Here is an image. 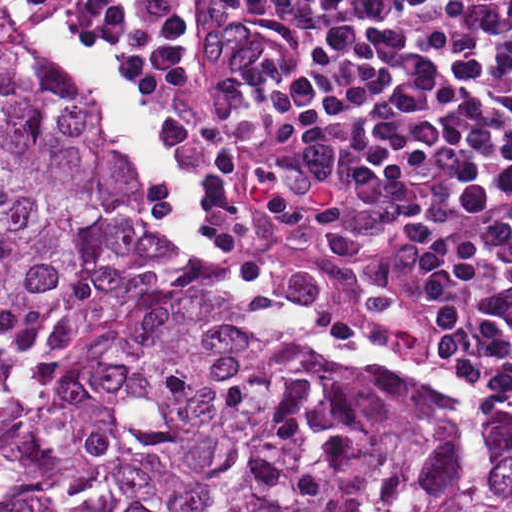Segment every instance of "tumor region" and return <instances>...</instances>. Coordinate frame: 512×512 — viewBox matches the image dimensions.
<instances>
[{
    "mask_svg": "<svg viewBox=\"0 0 512 512\" xmlns=\"http://www.w3.org/2000/svg\"><path fill=\"white\" fill-rule=\"evenodd\" d=\"M0 512H512V409L173 261L0 6Z\"/></svg>",
    "mask_w": 512,
    "mask_h": 512,
    "instance_id": "e687c5a6",
    "label": "tumor region"
}]
</instances>
